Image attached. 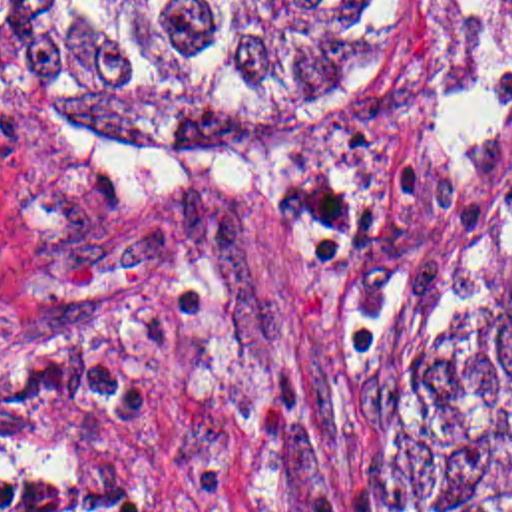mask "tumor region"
Returning a JSON list of instances; mask_svg holds the SVG:
<instances>
[{
  "label": "tumor region",
  "instance_id": "e687c5a6",
  "mask_svg": "<svg viewBox=\"0 0 512 512\" xmlns=\"http://www.w3.org/2000/svg\"><path fill=\"white\" fill-rule=\"evenodd\" d=\"M415 0H0V81L206 153H321L399 101ZM0 512H112L0 448ZM371 512H512V251L393 384Z\"/></svg>",
  "mask_w": 512,
  "mask_h": 512
}]
</instances>
